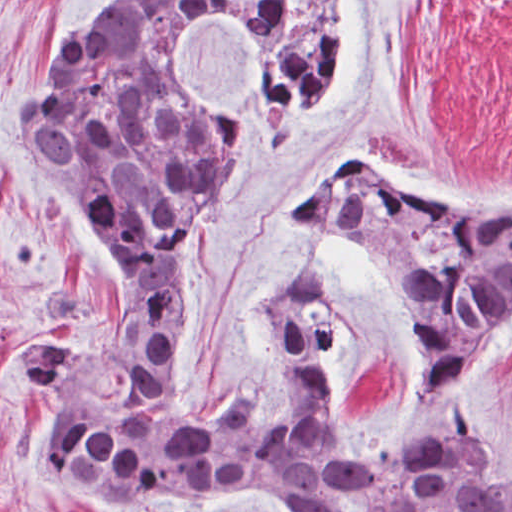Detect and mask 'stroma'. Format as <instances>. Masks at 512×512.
<instances>
[{"label":"stroma","mask_w":512,"mask_h":512,"mask_svg":"<svg viewBox=\"0 0 512 512\" xmlns=\"http://www.w3.org/2000/svg\"><path fill=\"white\" fill-rule=\"evenodd\" d=\"M142 1L0 0V512H98L38 462L37 439L53 400L17 381L10 363L27 344L113 325L126 287L21 139L18 112L60 38ZM342 53L339 103L313 136L285 145L231 34L203 30L188 51L239 126L225 199L206 232L192 237L181 277L183 321L169 380L179 411L193 421L215 418L235 396L270 419H299L265 328L262 285L313 254L331 268L341 304L334 358L341 412L380 431L406 409L414 316L387 260L356 226L291 217L329 169L363 165L466 205L512 204V0H345ZM46 275L82 284L96 300L92 316L37 315L28 291ZM473 381L471 426L512 464V348ZM113 512L263 511L229 491L149 493ZM332 512L379 510L339 493Z\"/></svg>","instance_id":"1"}]
</instances>
